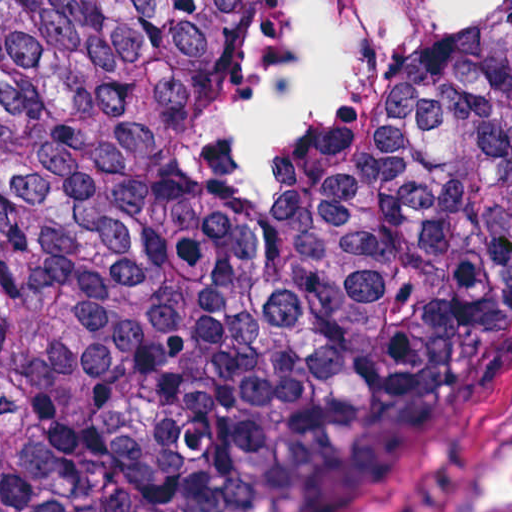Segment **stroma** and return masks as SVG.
I'll return each mask as SVG.
<instances>
[{
	"mask_svg": "<svg viewBox=\"0 0 512 512\" xmlns=\"http://www.w3.org/2000/svg\"><path fill=\"white\" fill-rule=\"evenodd\" d=\"M511 7L490 0L435 44ZM511 497L512 351L379 512H494Z\"/></svg>",
	"mask_w": 512,
	"mask_h": 512,
	"instance_id": "35a3bbf8",
	"label": "stroma"
}]
</instances>
